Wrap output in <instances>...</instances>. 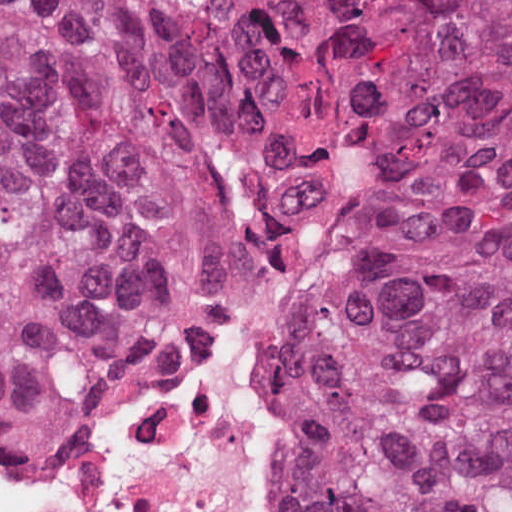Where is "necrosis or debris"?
<instances>
[{"mask_svg": "<svg viewBox=\"0 0 512 512\" xmlns=\"http://www.w3.org/2000/svg\"><path fill=\"white\" fill-rule=\"evenodd\" d=\"M332 220L304 215L259 270L168 348L101 434L52 459L0 443V512H278L268 344Z\"/></svg>", "mask_w": 512, "mask_h": 512, "instance_id": "1", "label": "necrosis or debris"}]
</instances>
